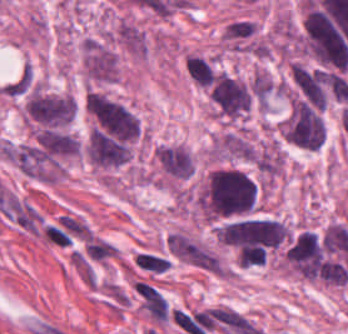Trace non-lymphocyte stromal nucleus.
Masks as SVG:
<instances>
[{
  "label": "non-lymphocyte stromal nucleus",
  "mask_w": 348,
  "mask_h": 334,
  "mask_svg": "<svg viewBox=\"0 0 348 334\" xmlns=\"http://www.w3.org/2000/svg\"><path fill=\"white\" fill-rule=\"evenodd\" d=\"M138 294L153 322H167L168 304L158 289L138 281Z\"/></svg>",
  "instance_id": "obj_3"
},
{
  "label": "non-lymphocyte stromal nucleus",
  "mask_w": 348,
  "mask_h": 334,
  "mask_svg": "<svg viewBox=\"0 0 348 334\" xmlns=\"http://www.w3.org/2000/svg\"><path fill=\"white\" fill-rule=\"evenodd\" d=\"M114 35L130 52L143 55L146 49L145 37L138 27L122 20Z\"/></svg>",
  "instance_id": "obj_4"
},
{
  "label": "non-lymphocyte stromal nucleus",
  "mask_w": 348,
  "mask_h": 334,
  "mask_svg": "<svg viewBox=\"0 0 348 334\" xmlns=\"http://www.w3.org/2000/svg\"><path fill=\"white\" fill-rule=\"evenodd\" d=\"M135 262L143 269L152 272H163L169 265L168 258L144 252H137Z\"/></svg>",
  "instance_id": "obj_6"
},
{
  "label": "non-lymphocyte stromal nucleus",
  "mask_w": 348,
  "mask_h": 334,
  "mask_svg": "<svg viewBox=\"0 0 348 334\" xmlns=\"http://www.w3.org/2000/svg\"><path fill=\"white\" fill-rule=\"evenodd\" d=\"M170 251L184 261L209 270H220L218 257L179 232H172L166 238Z\"/></svg>",
  "instance_id": "obj_2"
},
{
  "label": "non-lymphocyte stromal nucleus",
  "mask_w": 348,
  "mask_h": 334,
  "mask_svg": "<svg viewBox=\"0 0 348 334\" xmlns=\"http://www.w3.org/2000/svg\"><path fill=\"white\" fill-rule=\"evenodd\" d=\"M83 69L88 79L110 82L116 76L114 51L99 41L85 40L83 47Z\"/></svg>",
  "instance_id": "obj_1"
},
{
  "label": "non-lymphocyte stromal nucleus",
  "mask_w": 348,
  "mask_h": 334,
  "mask_svg": "<svg viewBox=\"0 0 348 334\" xmlns=\"http://www.w3.org/2000/svg\"><path fill=\"white\" fill-rule=\"evenodd\" d=\"M251 163L254 168L272 178L280 171V153L272 145L258 149L253 153Z\"/></svg>",
  "instance_id": "obj_5"
}]
</instances>
